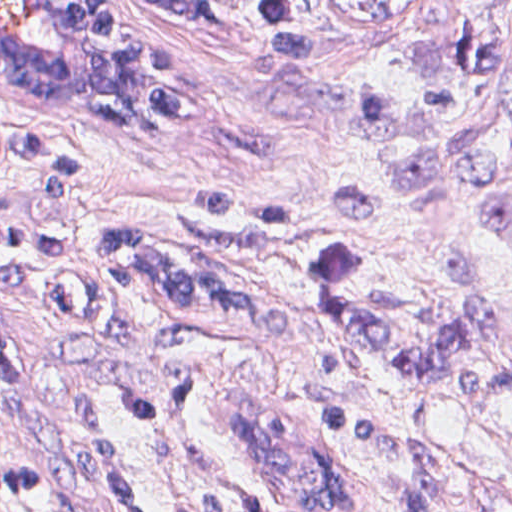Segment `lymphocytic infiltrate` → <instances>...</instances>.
I'll return each instance as SVG.
<instances>
[{
    "label": "lymphocytic infiltrate",
    "instance_id": "obj_1",
    "mask_svg": "<svg viewBox=\"0 0 512 512\" xmlns=\"http://www.w3.org/2000/svg\"><path fill=\"white\" fill-rule=\"evenodd\" d=\"M175 105L164 117L171 119ZM55 141H29L8 137L0 131V161H22L40 182L41 220L58 217L67 198L78 188L80 174L76 151L52 146ZM202 212L215 216V188L194 195ZM176 226L198 237L196 251L173 254L169 245L133 228L118 227L109 234L97 258L141 274L198 323L230 330L241 314L230 304L223 287L217 254L216 220L207 222L183 213ZM67 234L61 226L40 222L37 233L16 227L5 202H0V291H20L32 280L43 281V255L67 252ZM0 348L18 359L10 342L0 332ZM19 360V359H18Z\"/></svg>",
    "mask_w": 512,
    "mask_h": 512
}]
</instances>
